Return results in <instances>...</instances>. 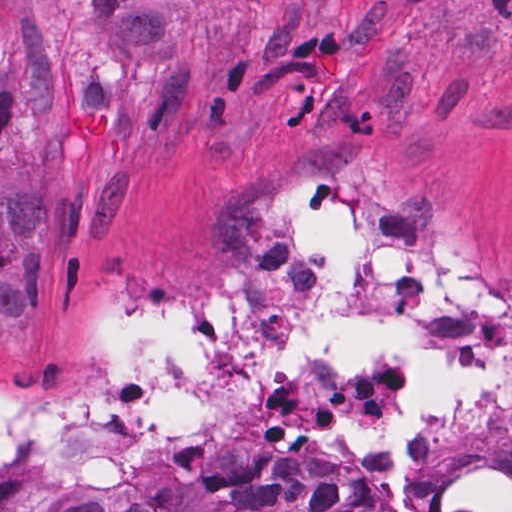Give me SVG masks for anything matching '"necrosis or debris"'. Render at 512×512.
<instances>
[{
    "instance_id": "1",
    "label": "necrosis or debris",
    "mask_w": 512,
    "mask_h": 512,
    "mask_svg": "<svg viewBox=\"0 0 512 512\" xmlns=\"http://www.w3.org/2000/svg\"><path fill=\"white\" fill-rule=\"evenodd\" d=\"M243 294H127L95 316L86 391L0 392V512H113L210 470L339 476L371 512H512V290L371 183L317 169L272 196Z\"/></svg>"
}]
</instances>
